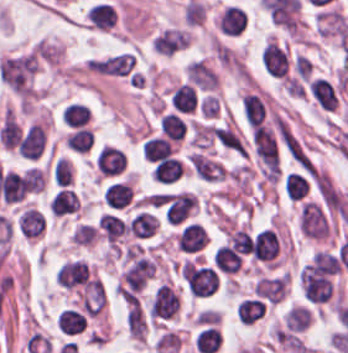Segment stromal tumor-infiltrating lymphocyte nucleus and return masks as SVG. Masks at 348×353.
<instances>
[{"instance_id":"obj_25","label":"stromal tumor-infiltrating lymphocyte nucleus","mask_w":348,"mask_h":353,"mask_svg":"<svg viewBox=\"0 0 348 353\" xmlns=\"http://www.w3.org/2000/svg\"><path fill=\"white\" fill-rule=\"evenodd\" d=\"M21 184L26 192H39L43 188L44 179L36 167H28L21 175Z\"/></svg>"},{"instance_id":"obj_2","label":"stromal tumor-infiltrating lymphocyte nucleus","mask_w":348,"mask_h":353,"mask_svg":"<svg viewBox=\"0 0 348 353\" xmlns=\"http://www.w3.org/2000/svg\"><path fill=\"white\" fill-rule=\"evenodd\" d=\"M262 65L271 78H286L291 71V57L280 42L269 38L263 44Z\"/></svg>"},{"instance_id":"obj_12","label":"stromal tumor-infiltrating lymphocyte nucleus","mask_w":348,"mask_h":353,"mask_svg":"<svg viewBox=\"0 0 348 353\" xmlns=\"http://www.w3.org/2000/svg\"><path fill=\"white\" fill-rule=\"evenodd\" d=\"M188 42L187 32L177 28H164L151 40V47L159 53L171 54Z\"/></svg>"},{"instance_id":"obj_16","label":"stromal tumor-infiltrating lymphocyte nucleus","mask_w":348,"mask_h":353,"mask_svg":"<svg viewBox=\"0 0 348 353\" xmlns=\"http://www.w3.org/2000/svg\"><path fill=\"white\" fill-rule=\"evenodd\" d=\"M134 54L121 52L114 55L95 59L94 69L107 73H126L133 61Z\"/></svg>"},{"instance_id":"obj_23","label":"stromal tumor-infiltrating lymphocyte nucleus","mask_w":348,"mask_h":353,"mask_svg":"<svg viewBox=\"0 0 348 353\" xmlns=\"http://www.w3.org/2000/svg\"><path fill=\"white\" fill-rule=\"evenodd\" d=\"M97 222L107 237L114 241L125 231V224L114 214L104 212L100 214Z\"/></svg>"},{"instance_id":"obj_22","label":"stromal tumor-infiltrating lymphocyte nucleus","mask_w":348,"mask_h":353,"mask_svg":"<svg viewBox=\"0 0 348 353\" xmlns=\"http://www.w3.org/2000/svg\"><path fill=\"white\" fill-rule=\"evenodd\" d=\"M94 135L89 129L79 127L64 140L67 147L73 151L86 152L93 143Z\"/></svg>"},{"instance_id":"obj_4","label":"stromal tumor-infiltrating lymphocyte nucleus","mask_w":348,"mask_h":353,"mask_svg":"<svg viewBox=\"0 0 348 353\" xmlns=\"http://www.w3.org/2000/svg\"><path fill=\"white\" fill-rule=\"evenodd\" d=\"M95 169L107 177H117L125 172L126 155L115 145L103 144L94 153Z\"/></svg>"},{"instance_id":"obj_6","label":"stromal tumor-infiltrating lymphocyte nucleus","mask_w":348,"mask_h":353,"mask_svg":"<svg viewBox=\"0 0 348 353\" xmlns=\"http://www.w3.org/2000/svg\"><path fill=\"white\" fill-rule=\"evenodd\" d=\"M306 85L308 93L317 107L325 111L333 110L338 96L331 79L325 75H311Z\"/></svg>"},{"instance_id":"obj_13","label":"stromal tumor-infiltrating lymphocyte nucleus","mask_w":348,"mask_h":353,"mask_svg":"<svg viewBox=\"0 0 348 353\" xmlns=\"http://www.w3.org/2000/svg\"><path fill=\"white\" fill-rule=\"evenodd\" d=\"M44 143V129L34 121L26 127L16 148L22 157L37 158Z\"/></svg>"},{"instance_id":"obj_24","label":"stromal tumor-infiltrating lymphocyte nucleus","mask_w":348,"mask_h":353,"mask_svg":"<svg viewBox=\"0 0 348 353\" xmlns=\"http://www.w3.org/2000/svg\"><path fill=\"white\" fill-rule=\"evenodd\" d=\"M285 193L291 198H300L307 189V182L300 173L289 172L285 175L284 182Z\"/></svg>"},{"instance_id":"obj_14","label":"stromal tumor-infiltrating lymphocyte nucleus","mask_w":348,"mask_h":353,"mask_svg":"<svg viewBox=\"0 0 348 353\" xmlns=\"http://www.w3.org/2000/svg\"><path fill=\"white\" fill-rule=\"evenodd\" d=\"M87 322L84 311L70 306L58 311L56 318L58 331L71 336L83 332Z\"/></svg>"},{"instance_id":"obj_9","label":"stromal tumor-infiltrating lymphocyte nucleus","mask_w":348,"mask_h":353,"mask_svg":"<svg viewBox=\"0 0 348 353\" xmlns=\"http://www.w3.org/2000/svg\"><path fill=\"white\" fill-rule=\"evenodd\" d=\"M15 228L23 238H38L43 234L42 209L23 207L15 217Z\"/></svg>"},{"instance_id":"obj_10","label":"stromal tumor-infiltrating lymphocyte nucleus","mask_w":348,"mask_h":353,"mask_svg":"<svg viewBox=\"0 0 348 353\" xmlns=\"http://www.w3.org/2000/svg\"><path fill=\"white\" fill-rule=\"evenodd\" d=\"M257 260L272 261L279 250V241L275 230L263 228L259 231L250 247Z\"/></svg>"},{"instance_id":"obj_1","label":"stromal tumor-infiltrating lymphocyte nucleus","mask_w":348,"mask_h":353,"mask_svg":"<svg viewBox=\"0 0 348 353\" xmlns=\"http://www.w3.org/2000/svg\"><path fill=\"white\" fill-rule=\"evenodd\" d=\"M179 309V296L171 283L157 285L150 294L147 313L157 321L172 318Z\"/></svg>"},{"instance_id":"obj_5","label":"stromal tumor-infiltrating lymphocyte nucleus","mask_w":348,"mask_h":353,"mask_svg":"<svg viewBox=\"0 0 348 353\" xmlns=\"http://www.w3.org/2000/svg\"><path fill=\"white\" fill-rule=\"evenodd\" d=\"M134 190L130 182L120 178L110 179L102 190V199L105 207L110 210H120L131 204Z\"/></svg>"},{"instance_id":"obj_21","label":"stromal tumor-infiltrating lymphocyte nucleus","mask_w":348,"mask_h":353,"mask_svg":"<svg viewBox=\"0 0 348 353\" xmlns=\"http://www.w3.org/2000/svg\"><path fill=\"white\" fill-rule=\"evenodd\" d=\"M53 184L57 187L72 181L73 167L70 160L56 157L49 170Z\"/></svg>"},{"instance_id":"obj_7","label":"stromal tumor-infiltrating lymphocyte nucleus","mask_w":348,"mask_h":353,"mask_svg":"<svg viewBox=\"0 0 348 353\" xmlns=\"http://www.w3.org/2000/svg\"><path fill=\"white\" fill-rule=\"evenodd\" d=\"M85 24L98 31H108L115 26L116 9L109 1L97 0L84 11Z\"/></svg>"},{"instance_id":"obj_3","label":"stromal tumor-infiltrating lymphocyte nucleus","mask_w":348,"mask_h":353,"mask_svg":"<svg viewBox=\"0 0 348 353\" xmlns=\"http://www.w3.org/2000/svg\"><path fill=\"white\" fill-rule=\"evenodd\" d=\"M207 241L204 226L198 222L187 220L180 224L175 233L177 250L187 255H195L203 250Z\"/></svg>"},{"instance_id":"obj_19","label":"stromal tumor-infiltrating lymphocyte nucleus","mask_w":348,"mask_h":353,"mask_svg":"<svg viewBox=\"0 0 348 353\" xmlns=\"http://www.w3.org/2000/svg\"><path fill=\"white\" fill-rule=\"evenodd\" d=\"M90 117V109L88 105L69 102L66 104L62 113V120L67 125L81 126L88 121Z\"/></svg>"},{"instance_id":"obj_15","label":"stromal tumor-infiltrating lymphocyte nucleus","mask_w":348,"mask_h":353,"mask_svg":"<svg viewBox=\"0 0 348 353\" xmlns=\"http://www.w3.org/2000/svg\"><path fill=\"white\" fill-rule=\"evenodd\" d=\"M218 26L223 33L238 34L246 26V13L236 5L226 6L218 17Z\"/></svg>"},{"instance_id":"obj_18","label":"stromal tumor-infiltrating lymphocyte nucleus","mask_w":348,"mask_h":353,"mask_svg":"<svg viewBox=\"0 0 348 353\" xmlns=\"http://www.w3.org/2000/svg\"><path fill=\"white\" fill-rule=\"evenodd\" d=\"M265 310L263 301L254 297L243 299L237 306L238 318L240 322H254Z\"/></svg>"},{"instance_id":"obj_26","label":"stromal tumor-infiltrating lymphocyte nucleus","mask_w":348,"mask_h":353,"mask_svg":"<svg viewBox=\"0 0 348 353\" xmlns=\"http://www.w3.org/2000/svg\"><path fill=\"white\" fill-rule=\"evenodd\" d=\"M229 245L235 251L247 253L250 250V238L244 229H237L229 235Z\"/></svg>"},{"instance_id":"obj_20","label":"stromal tumor-infiltrating lymphocyte nucleus","mask_w":348,"mask_h":353,"mask_svg":"<svg viewBox=\"0 0 348 353\" xmlns=\"http://www.w3.org/2000/svg\"><path fill=\"white\" fill-rule=\"evenodd\" d=\"M170 98L181 111H192L196 100L192 85L184 82L171 92Z\"/></svg>"},{"instance_id":"obj_17","label":"stromal tumor-infiltrating lymphocyte nucleus","mask_w":348,"mask_h":353,"mask_svg":"<svg viewBox=\"0 0 348 353\" xmlns=\"http://www.w3.org/2000/svg\"><path fill=\"white\" fill-rule=\"evenodd\" d=\"M284 281V274L262 276L256 281L254 292L266 300L277 302L282 296Z\"/></svg>"},{"instance_id":"obj_11","label":"stromal tumor-infiltrating lymphocyte nucleus","mask_w":348,"mask_h":353,"mask_svg":"<svg viewBox=\"0 0 348 353\" xmlns=\"http://www.w3.org/2000/svg\"><path fill=\"white\" fill-rule=\"evenodd\" d=\"M193 342L196 352L214 353L222 343V334L218 326L204 322L197 326Z\"/></svg>"},{"instance_id":"obj_8","label":"stromal tumor-infiltrating lymphocyte nucleus","mask_w":348,"mask_h":353,"mask_svg":"<svg viewBox=\"0 0 348 353\" xmlns=\"http://www.w3.org/2000/svg\"><path fill=\"white\" fill-rule=\"evenodd\" d=\"M188 118L181 111H161L157 132L172 140H182L187 135Z\"/></svg>"}]
</instances>
